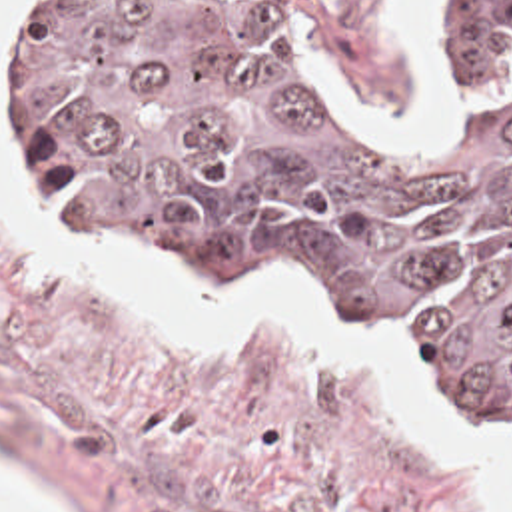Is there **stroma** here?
I'll use <instances>...</instances> for the list:
<instances>
[{"mask_svg": "<svg viewBox=\"0 0 512 512\" xmlns=\"http://www.w3.org/2000/svg\"><path fill=\"white\" fill-rule=\"evenodd\" d=\"M0 20V168L6 166V40ZM385 132L437 144V126H405L411 94L397 50L401 0H277ZM429 0H415V30ZM512 0H505V32ZM18 214L50 232L54 252L98 254L62 238L10 186ZM108 262V260H106ZM168 290L279 294L355 330L401 360L473 442L512 460L401 350L313 296L269 280H158ZM0 483L48 512H477L469 470L369 372L299 342L279 320L255 340L202 354L146 312L46 270L0 220Z\"/></svg>", "mask_w": 512, "mask_h": 512, "instance_id": "1", "label": "stroma"}]
</instances>
